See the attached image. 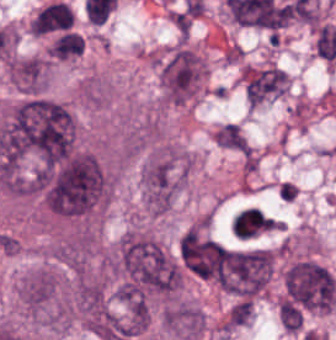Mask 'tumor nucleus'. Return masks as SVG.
I'll return each mask as SVG.
<instances>
[{
  "label": "tumor nucleus",
  "mask_w": 336,
  "mask_h": 340,
  "mask_svg": "<svg viewBox=\"0 0 336 340\" xmlns=\"http://www.w3.org/2000/svg\"><path fill=\"white\" fill-rule=\"evenodd\" d=\"M190 173L189 156L178 147L153 146L140 170L143 209L170 210L183 191Z\"/></svg>",
  "instance_id": "tumor-nucleus-1"
},
{
  "label": "tumor nucleus",
  "mask_w": 336,
  "mask_h": 340,
  "mask_svg": "<svg viewBox=\"0 0 336 340\" xmlns=\"http://www.w3.org/2000/svg\"><path fill=\"white\" fill-rule=\"evenodd\" d=\"M254 303L252 300H238L230 306L225 318V325L231 327L246 326L252 321Z\"/></svg>",
  "instance_id": "tumor-nucleus-6"
},
{
  "label": "tumor nucleus",
  "mask_w": 336,
  "mask_h": 340,
  "mask_svg": "<svg viewBox=\"0 0 336 340\" xmlns=\"http://www.w3.org/2000/svg\"><path fill=\"white\" fill-rule=\"evenodd\" d=\"M220 147L233 151H247L249 142L237 124L226 123L217 128L212 136Z\"/></svg>",
  "instance_id": "tumor-nucleus-5"
},
{
  "label": "tumor nucleus",
  "mask_w": 336,
  "mask_h": 340,
  "mask_svg": "<svg viewBox=\"0 0 336 340\" xmlns=\"http://www.w3.org/2000/svg\"><path fill=\"white\" fill-rule=\"evenodd\" d=\"M164 328L176 340H194L205 331L204 313L194 302L176 299L163 311Z\"/></svg>",
  "instance_id": "tumor-nucleus-3"
},
{
  "label": "tumor nucleus",
  "mask_w": 336,
  "mask_h": 340,
  "mask_svg": "<svg viewBox=\"0 0 336 340\" xmlns=\"http://www.w3.org/2000/svg\"><path fill=\"white\" fill-rule=\"evenodd\" d=\"M18 301L26 314L42 325L65 329L71 309L61 273L51 267H37L18 284Z\"/></svg>",
  "instance_id": "tumor-nucleus-2"
},
{
  "label": "tumor nucleus",
  "mask_w": 336,
  "mask_h": 340,
  "mask_svg": "<svg viewBox=\"0 0 336 340\" xmlns=\"http://www.w3.org/2000/svg\"><path fill=\"white\" fill-rule=\"evenodd\" d=\"M279 313L285 331H299L303 318L301 311L289 300L279 299Z\"/></svg>",
  "instance_id": "tumor-nucleus-7"
},
{
  "label": "tumor nucleus",
  "mask_w": 336,
  "mask_h": 340,
  "mask_svg": "<svg viewBox=\"0 0 336 340\" xmlns=\"http://www.w3.org/2000/svg\"><path fill=\"white\" fill-rule=\"evenodd\" d=\"M51 63L42 56L12 57L5 70L17 90L28 93L46 92Z\"/></svg>",
  "instance_id": "tumor-nucleus-4"
}]
</instances>
